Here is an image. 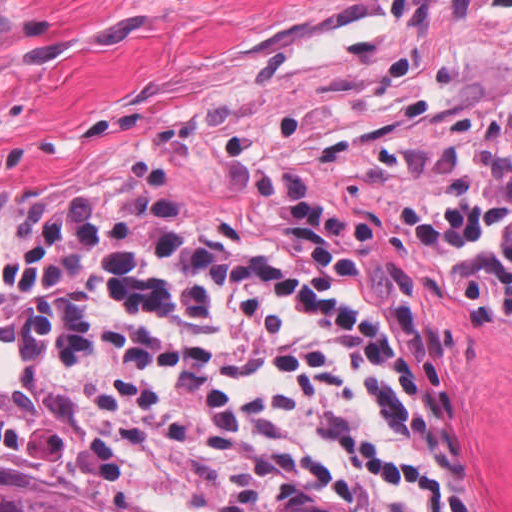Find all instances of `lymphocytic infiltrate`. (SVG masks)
Listing matches in <instances>:
<instances>
[{"label": "lymphocytic infiltrate", "mask_w": 512, "mask_h": 512, "mask_svg": "<svg viewBox=\"0 0 512 512\" xmlns=\"http://www.w3.org/2000/svg\"><path fill=\"white\" fill-rule=\"evenodd\" d=\"M407 240L465 330L512 341V81L412 139ZM31 340L0 453L195 491L227 512H478L444 454V372L348 199H303L279 260L77 203L3 251Z\"/></svg>", "instance_id": "1"}]
</instances>
